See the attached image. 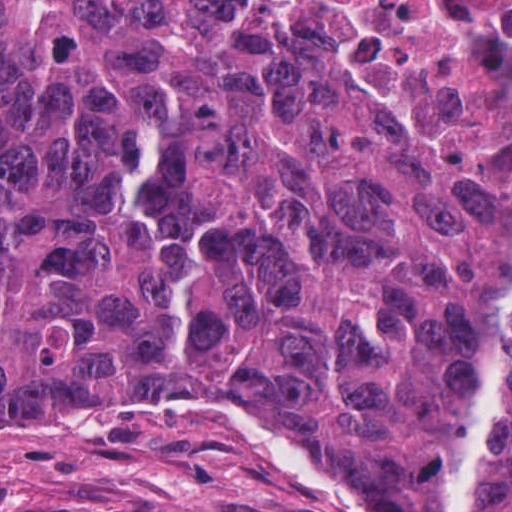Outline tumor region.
I'll use <instances>...</instances> for the list:
<instances>
[{
    "instance_id": "tumor-region-1",
    "label": "tumor region",
    "mask_w": 512,
    "mask_h": 512,
    "mask_svg": "<svg viewBox=\"0 0 512 512\" xmlns=\"http://www.w3.org/2000/svg\"><path fill=\"white\" fill-rule=\"evenodd\" d=\"M141 411L268 512H512V203L206 0H0V415Z\"/></svg>"
}]
</instances>
